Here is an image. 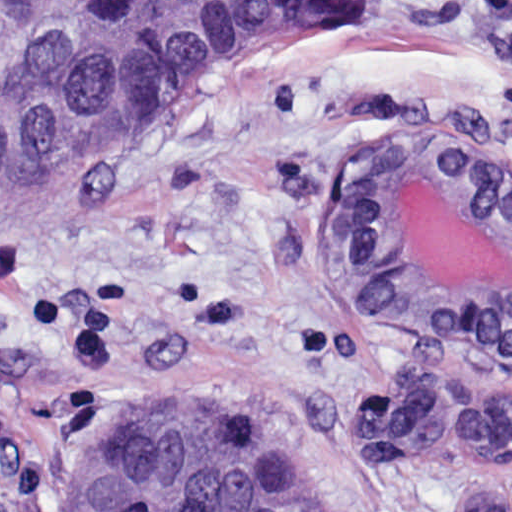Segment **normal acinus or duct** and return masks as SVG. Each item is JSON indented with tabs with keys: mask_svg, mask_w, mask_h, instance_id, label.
Segmentation results:
<instances>
[{
	"mask_svg": "<svg viewBox=\"0 0 512 512\" xmlns=\"http://www.w3.org/2000/svg\"><path fill=\"white\" fill-rule=\"evenodd\" d=\"M473 137H385L345 223L384 327L512 358V175Z\"/></svg>",
	"mask_w": 512,
	"mask_h": 512,
	"instance_id": "normal-acinus-or-duct-1",
	"label": "normal acinus or duct"
}]
</instances>
